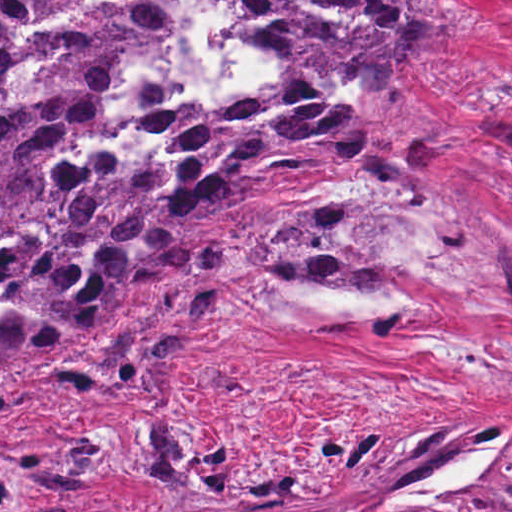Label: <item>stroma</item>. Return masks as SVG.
<instances>
[{"instance_id":"35a3bbf8","label":"stroma","mask_w":512,"mask_h":512,"mask_svg":"<svg viewBox=\"0 0 512 512\" xmlns=\"http://www.w3.org/2000/svg\"><path fill=\"white\" fill-rule=\"evenodd\" d=\"M470 25L402 93L440 140L396 172L312 170L245 180L204 247L266 214H348L343 240L384 270L369 287L259 280L208 313L148 393L32 375L78 346L4 361L24 392L0 430L100 429L105 471L0 512H343L491 436L461 493L422 510L512 512V0H451Z\"/></svg>"}]
</instances>
